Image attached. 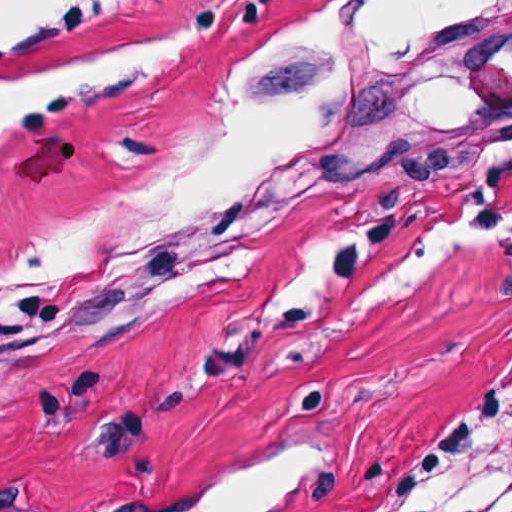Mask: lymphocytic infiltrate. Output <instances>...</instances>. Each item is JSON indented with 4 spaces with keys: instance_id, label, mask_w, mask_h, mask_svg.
<instances>
[{
    "instance_id": "f902f5d3",
    "label": "lymphocytic infiltrate",
    "mask_w": 512,
    "mask_h": 512,
    "mask_svg": "<svg viewBox=\"0 0 512 512\" xmlns=\"http://www.w3.org/2000/svg\"><path fill=\"white\" fill-rule=\"evenodd\" d=\"M122 0H66L75 5H116ZM478 512H512V492L499 502Z\"/></svg>"
}]
</instances>
